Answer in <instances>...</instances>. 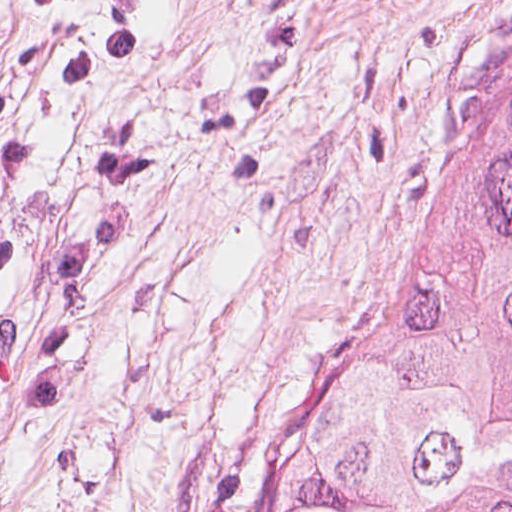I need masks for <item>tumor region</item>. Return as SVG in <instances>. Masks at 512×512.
<instances>
[{
  "label": "tumor region",
  "mask_w": 512,
  "mask_h": 512,
  "mask_svg": "<svg viewBox=\"0 0 512 512\" xmlns=\"http://www.w3.org/2000/svg\"><path fill=\"white\" fill-rule=\"evenodd\" d=\"M269 512H512V123Z\"/></svg>",
  "instance_id": "tumor-region-1"
}]
</instances>
